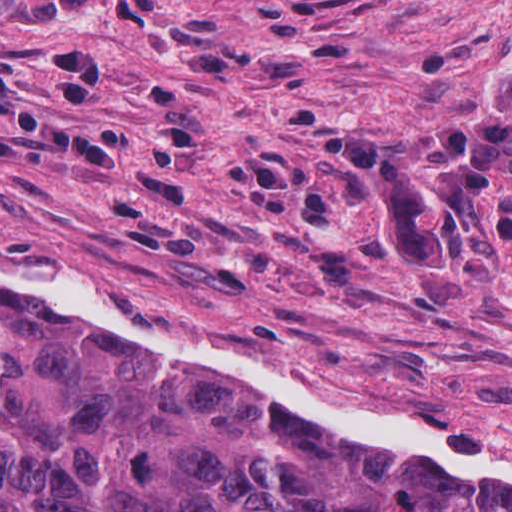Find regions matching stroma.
Returning <instances> with one entry per match:
<instances>
[{
	"label": "stroma",
	"mask_w": 512,
	"mask_h": 512,
	"mask_svg": "<svg viewBox=\"0 0 512 512\" xmlns=\"http://www.w3.org/2000/svg\"><path fill=\"white\" fill-rule=\"evenodd\" d=\"M511 70L512 0H0V246L512 463Z\"/></svg>",
	"instance_id": "stroma-1"
}]
</instances>
